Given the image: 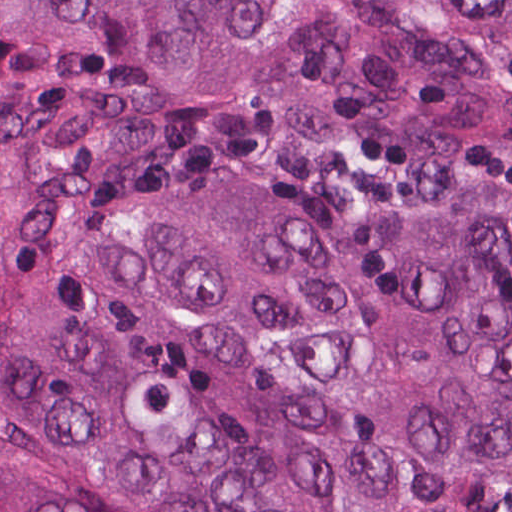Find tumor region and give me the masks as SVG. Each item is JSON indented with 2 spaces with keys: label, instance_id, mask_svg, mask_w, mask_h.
I'll return each instance as SVG.
<instances>
[{
  "label": "tumor region",
  "instance_id": "tumor-region-1",
  "mask_svg": "<svg viewBox=\"0 0 512 512\" xmlns=\"http://www.w3.org/2000/svg\"><path fill=\"white\" fill-rule=\"evenodd\" d=\"M0 512H512V0H0Z\"/></svg>",
  "mask_w": 512,
  "mask_h": 512
}]
</instances>
